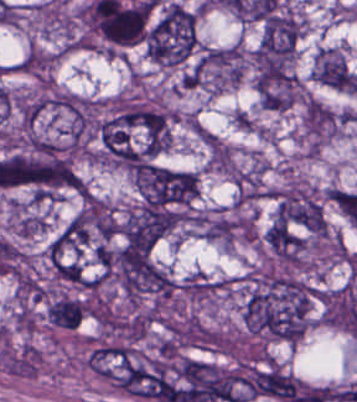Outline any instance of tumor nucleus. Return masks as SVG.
I'll use <instances>...</instances> for the list:
<instances>
[{
  "instance_id": "1",
  "label": "tumor nucleus",
  "mask_w": 357,
  "mask_h": 402,
  "mask_svg": "<svg viewBox=\"0 0 357 402\" xmlns=\"http://www.w3.org/2000/svg\"><path fill=\"white\" fill-rule=\"evenodd\" d=\"M129 173L139 202L174 216L190 213L197 194L196 173L149 161Z\"/></svg>"
},
{
  "instance_id": "2",
  "label": "tumor nucleus",
  "mask_w": 357,
  "mask_h": 402,
  "mask_svg": "<svg viewBox=\"0 0 357 402\" xmlns=\"http://www.w3.org/2000/svg\"><path fill=\"white\" fill-rule=\"evenodd\" d=\"M145 54L164 66H176L198 46L197 11L170 1L147 25Z\"/></svg>"
},
{
  "instance_id": "3",
  "label": "tumor nucleus",
  "mask_w": 357,
  "mask_h": 402,
  "mask_svg": "<svg viewBox=\"0 0 357 402\" xmlns=\"http://www.w3.org/2000/svg\"><path fill=\"white\" fill-rule=\"evenodd\" d=\"M271 217L309 234L324 235L326 225L321 198L298 181H288L269 190Z\"/></svg>"
},
{
  "instance_id": "4",
  "label": "tumor nucleus",
  "mask_w": 357,
  "mask_h": 402,
  "mask_svg": "<svg viewBox=\"0 0 357 402\" xmlns=\"http://www.w3.org/2000/svg\"><path fill=\"white\" fill-rule=\"evenodd\" d=\"M171 228V214L167 208L138 202L121 218L116 234L121 254L151 248Z\"/></svg>"
},
{
  "instance_id": "5",
  "label": "tumor nucleus",
  "mask_w": 357,
  "mask_h": 402,
  "mask_svg": "<svg viewBox=\"0 0 357 402\" xmlns=\"http://www.w3.org/2000/svg\"><path fill=\"white\" fill-rule=\"evenodd\" d=\"M243 55L239 44L207 47L199 57L200 84L220 91L240 78Z\"/></svg>"
},
{
  "instance_id": "6",
  "label": "tumor nucleus",
  "mask_w": 357,
  "mask_h": 402,
  "mask_svg": "<svg viewBox=\"0 0 357 402\" xmlns=\"http://www.w3.org/2000/svg\"><path fill=\"white\" fill-rule=\"evenodd\" d=\"M265 243L273 257L288 267H295L301 260L304 240L279 216L267 227Z\"/></svg>"
},
{
  "instance_id": "7",
  "label": "tumor nucleus",
  "mask_w": 357,
  "mask_h": 402,
  "mask_svg": "<svg viewBox=\"0 0 357 402\" xmlns=\"http://www.w3.org/2000/svg\"><path fill=\"white\" fill-rule=\"evenodd\" d=\"M303 122L311 145H319L336 134V116L314 98L306 99L303 105Z\"/></svg>"
},
{
  "instance_id": "8",
  "label": "tumor nucleus",
  "mask_w": 357,
  "mask_h": 402,
  "mask_svg": "<svg viewBox=\"0 0 357 402\" xmlns=\"http://www.w3.org/2000/svg\"><path fill=\"white\" fill-rule=\"evenodd\" d=\"M86 310L81 297L59 294L45 306V318L61 329H76Z\"/></svg>"
}]
</instances>
